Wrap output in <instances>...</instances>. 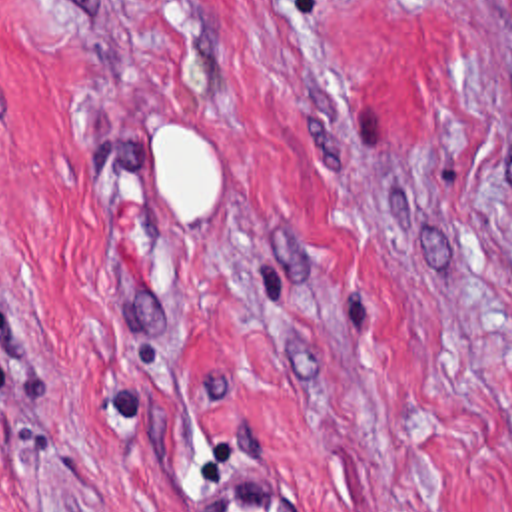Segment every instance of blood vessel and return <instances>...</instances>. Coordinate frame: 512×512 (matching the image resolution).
<instances>
[{"instance_id": "8fb6f2fc", "label": "blood vessel", "mask_w": 512, "mask_h": 512, "mask_svg": "<svg viewBox=\"0 0 512 512\" xmlns=\"http://www.w3.org/2000/svg\"><path fill=\"white\" fill-rule=\"evenodd\" d=\"M193 512H319L305 487L275 467H249L203 493Z\"/></svg>"}]
</instances>
